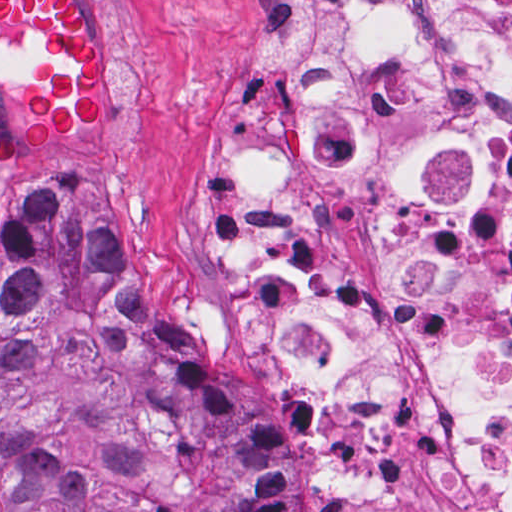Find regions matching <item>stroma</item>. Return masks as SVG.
<instances>
[{
    "label": "stroma",
    "mask_w": 512,
    "mask_h": 512,
    "mask_svg": "<svg viewBox=\"0 0 512 512\" xmlns=\"http://www.w3.org/2000/svg\"><path fill=\"white\" fill-rule=\"evenodd\" d=\"M246 1L75 0L102 43L104 115L86 136L12 156L0 171V217L45 171L80 168L97 180L125 255L161 294L187 343L246 388L286 437L289 512H320L323 465L304 444L289 388L271 369L263 339L209 282L202 222ZM18 85L19 62L0 60L2 142H10ZM1 270L0 254V288Z\"/></svg>",
    "instance_id": "35a3bbf8"
}]
</instances>
